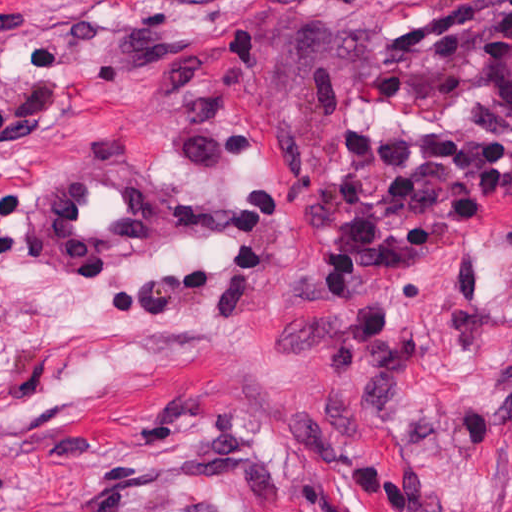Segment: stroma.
I'll return each mask as SVG.
<instances>
[{
	"instance_id": "obj_1",
	"label": "stroma",
	"mask_w": 512,
	"mask_h": 512,
	"mask_svg": "<svg viewBox=\"0 0 512 512\" xmlns=\"http://www.w3.org/2000/svg\"><path fill=\"white\" fill-rule=\"evenodd\" d=\"M0 512H512V0H0Z\"/></svg>"
}]
</instances>
